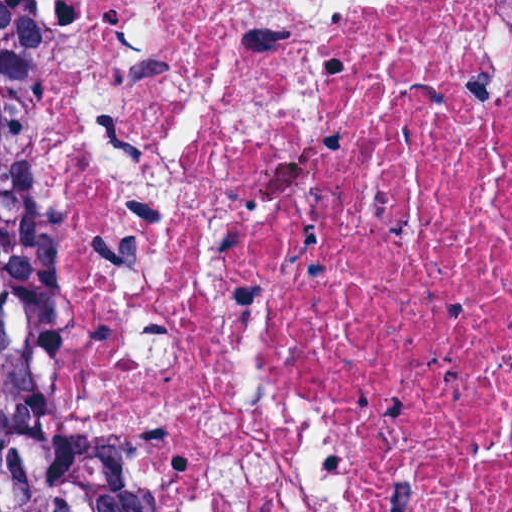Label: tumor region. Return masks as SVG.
<instances>
[{"mask_svg":"<svg viewBox=\"0 0 512 512\" xmlns=\"http://www.w3.org/2000/svg\"><path fill=\"white\" fill-rule=\"evenodd\" d=\"M11 86L0 54V131ZM0 512H130L108 457L41 407L1 315Z\"/></svg>","mask_w":512,"mask_h":512,"instance_id":"obj_1","label":"tumor region"}]
</instances>
